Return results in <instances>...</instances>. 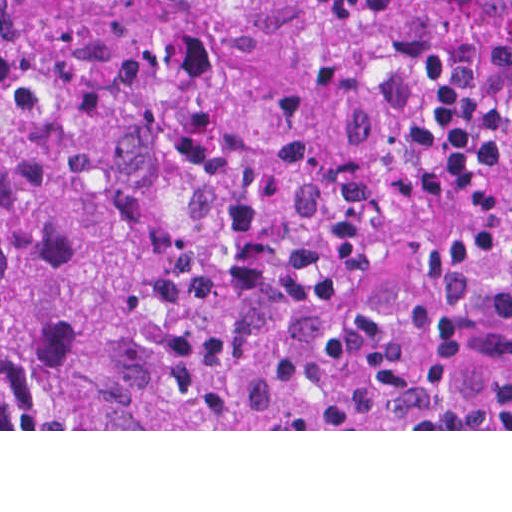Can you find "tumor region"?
Listing matches in <instances>:
<instances>
[{"label":"tumor region","instance_id":"e687c5a6","mask_svg":"<svg viewBox=\"0 0 512 512\" xmlns=\"http://www.w3.org/2000/svg\"><path fill=\"white\" fill-rule=\"evenodd\" d=\"M0 429H512V0H0Z\"/></svg>","mask_w":512,"mask_h":512}]
</instances>
